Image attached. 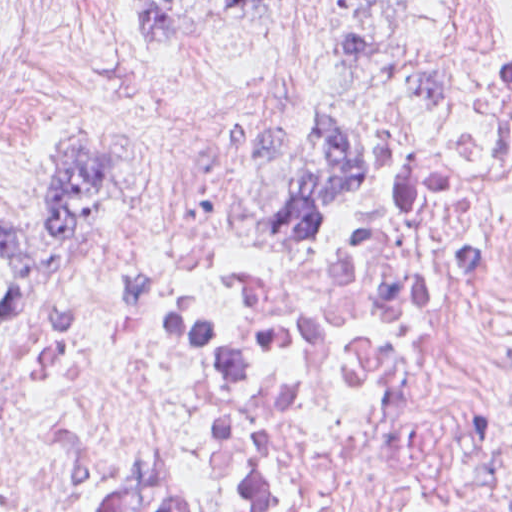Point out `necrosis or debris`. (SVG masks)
<instances>
[{"mask_svg":"<svg viewBox=\"0 0 512 512\" xmlns=\"http://www.w3.org/2000/svg\"><path fill=\"white\" fill-rule=\"evenodd\" d=\"M330 280L210 249L76 285L0 366V512H512V61Z\"/></svg>","mask_w":512,"mask_h":512,"instance_id":"1","label":"necrosis or debris"}]
</instances>
